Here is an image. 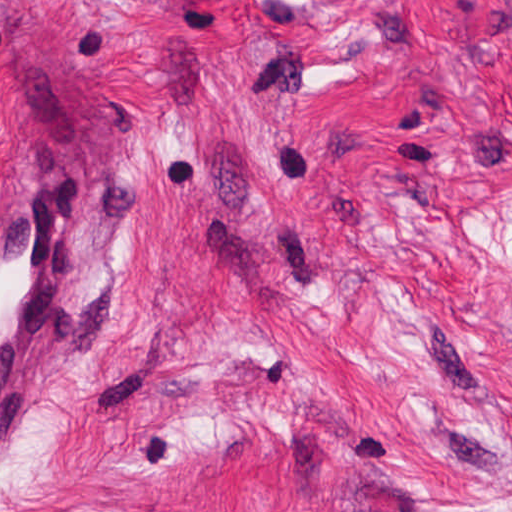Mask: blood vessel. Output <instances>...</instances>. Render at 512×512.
Here are the masks:
<instances>
[{
	"label": "blood vessel",
	"instance_id": "obj_1",
	"mask_svg": "<svg viewBox=\"0 0 512 512\" xmlns=\"http://www.w3.org/2000/svg\"><path fill=\"white\" fill-rule=\"evenodd\" d=\"M80 167L55 160L0 185V430L35 402L68 328L67 261L78 277Z\"/></svg>",
	"mask_w": 512,
	"mask_h": 512
}]
</instances>
